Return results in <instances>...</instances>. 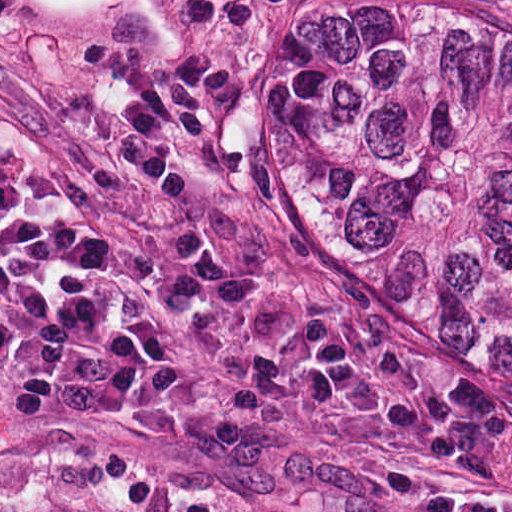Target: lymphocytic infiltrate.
Instances as JSON below:
<instances>
[{
    "instance_id": "lymphocytic-infiltrate-1",
    "label": "lymphocytic infiltrate",
    "mask_w": 512,
    "mask_h": 512,
    "mask_svg": "<svg viewBox=\"0 0 512 512\" xmlns=\"http://www.w3.org/2000/svg\"><path fill=\"white\" fill-rule=\"evenodd\" d=\"M182 359L137 308L0 258V412L72 423L172 402Z\"/></svg>"
}]
</instances>
